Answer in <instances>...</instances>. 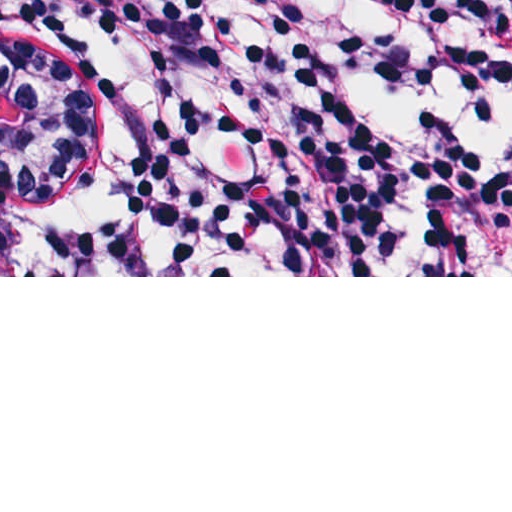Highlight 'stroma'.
Here are the masks:
<instances>
[{"instance_id": "obj_1", "label": "stroma", "mask_w": 512, "mask_h": 512, "mask_svg": "<svg viewBox=\"0 0 512 512\" xmlns=\"http://www.w3.org/2000/svg\"><path fill=\"white\" fill-rule=\"evenodd\" d=\"M89 208L86 149L51 97L0 64V277L82 276L76 238Z\"/></svg>"}]
</instances>
